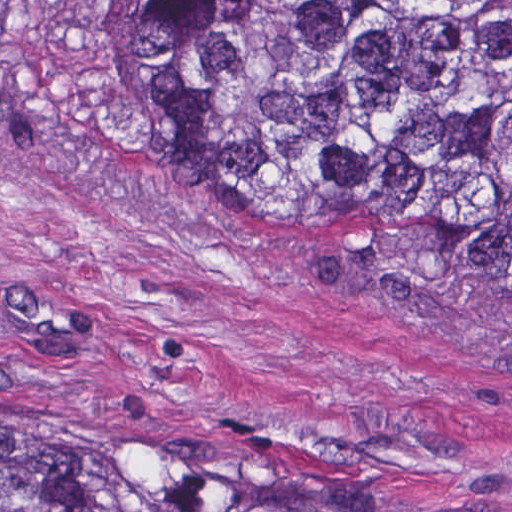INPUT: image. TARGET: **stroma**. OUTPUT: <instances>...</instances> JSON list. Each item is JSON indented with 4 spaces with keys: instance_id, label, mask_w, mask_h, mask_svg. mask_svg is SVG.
Masks as SVG:
<instances>
[{
    "instance_id": "35a3bbf8",
    "label": "stroma",
    "mask_w": 512,
    "mask_h": 512,
    "mask_svg": "<svg viewBox=\"0 0 512 512\" xmlns=\"http://www.w3.org/2000/svg\"><path fill=\"white\" fill-rule=\"evenodd\" d=\"M1 409L118 414L321 505L512 512V301L147 171L86 0H0Z\"/></svg>"
}]
</instances>
